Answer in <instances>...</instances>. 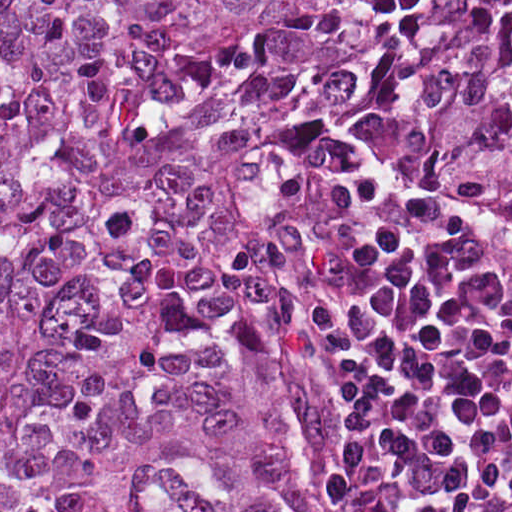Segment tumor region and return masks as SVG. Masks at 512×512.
Segmentation results:
<instances>
[{
  "label": "tumor region",
  "mask_w": 512,
  "mask_h": 512,
  "mask_svg": "<svg viewBox=\"0 0 512 512\" xmlns=\"http://www.w3.org/2000/svg\"><path fill=\"white\" fill-rule=\"evenodd\" d=\"M357 149L512 217V0H0V512H334L274 294Z\"/></svg>",
  "instance_id": "e687c5a6"
}]
</instances>
